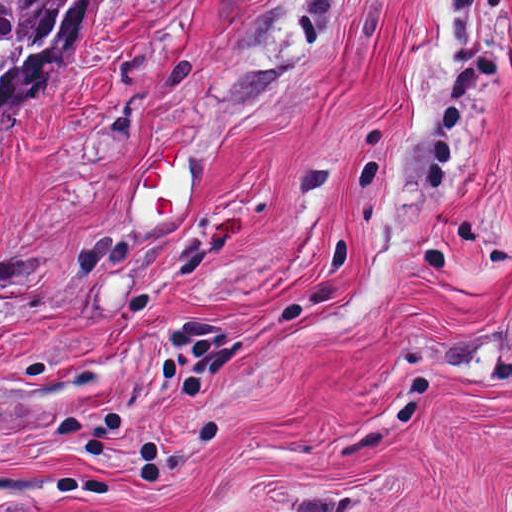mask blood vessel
I'll list each match as a JSON object with an SVG mask.
<instances>
[{
    "mask_svg": "<svg viewBox=\"0 0 512 512\" xmlns=\"http://www.w3.org/2000/svg\"><path fill=\"white\" fill-rule=\"evenodd\" d=\"M181 198V148L173 139L157 142L155 153L137 170L134 211L144 221H161Z\"/></svg>",
    "mask_w": 512,
    "mask_h": 512,
    "instance_id": "obj_1",
    "label": "blood vessel"
}]
</instances>
